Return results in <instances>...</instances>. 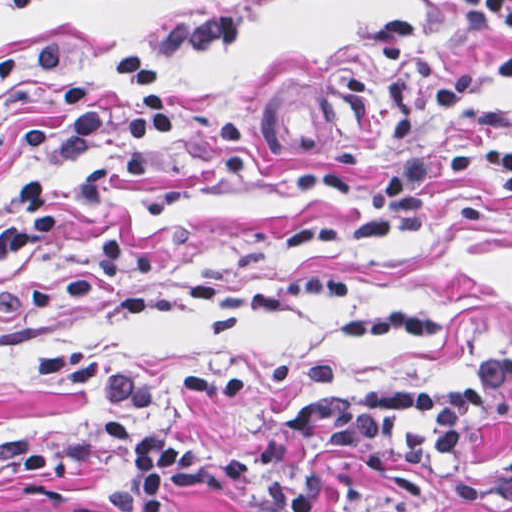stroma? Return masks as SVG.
Wrapping results in <instances>:
<instances>
[{"instance_id": "1", "label": "stroma", "mask_w": 512, "mask_h": 512, "mask_svg": "<svg viewBox=\"0 0 512 512\" xmlns=\"http://www.w3.org/2000/svg\"><path fill=\"white\" fill-rule=\"evenodd\" d=\"M454 0H113L12 13L0 0V192L56 91L34 70L62 44L101 109L141 34L176 15L237 12L228 45L144 54L180 115L157 170L126 175L111 140L55 161L57 223L0 243V512H111L125 451L103 422L173 431L219 451L262 449L305 400L459 383L512 356V185L490 170L433 181L423 219L348 246L289 244L307 218L361 209L296 184L322 172L268 153L253 92L325 82L362 106L324 171L368 192L420 142L512 144V29ZM325 485L317 512H458L447 490L512 463V404L447 468L363 472L290 453ZM162 512H250L179 495ZM505 512H512L511 510Z\"/></svg>"}]
</instances>
